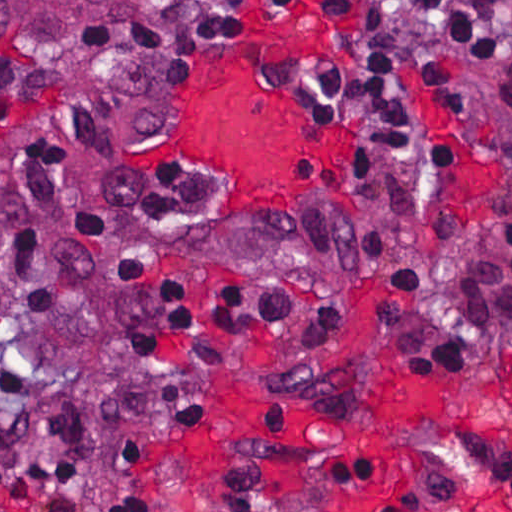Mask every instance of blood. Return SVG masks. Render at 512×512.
Wrapping results in <instances>:
<instances>
[{
  "instance_id": "obj_1",
  "label": "blood",
  "mask_w": 512,
  "mask_h": 512,
  "mask_svg": "<svg viewBox=\"0 0 512 512\" xmlns=\"http://www.w3.org/2000/svg\"><path fill=\"white\" fill-rule=\"evenodd\" d=\"M316 19L287 20L223 63L189 118L180 159L220 173L240 206L306 209L319 182L345 162L343 149L315 139L301 105L285 94L247 92L259 54L286 41L328 35ZM400 435L422 444L432 481L324 409L301 405L268 380L245 379L230 427L185 451L191 487L227 502L321 503L330 512H512L472 458L444 402L409 388L387 391ZM512 415V361H511Z\"/></svg>"
}]
</instances>
